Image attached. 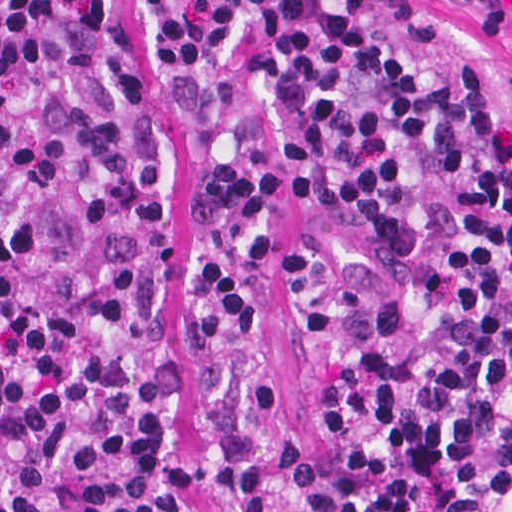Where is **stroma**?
Masks as SVG:
<instances>
[{
	"label": "stroma",
	"mask_w": 512,
	"mask_h": 512,
	"mask_svg": "<svg viewBox=\"0 0 512 512\" xmlns=\"http://www.w3.org/2000/svg\"><path fill=\"white\" fill-rule=\"evenodd\" d=\"M453 49L483 92L512 126V0H430ZM124 28L135 69L149 88L168 144L170 220L163 246L156 305L179 335L196 326V269L220 261L247 303L246 336L205 347L183 360L179 410L196 403L213 382H273L275 406L241 423L196 422L179 438L191 461L188 512H223L211 483L241 469L277 462L311 449V367L291 318L282 266L303 243L325 248L356 265L369 253L362 231L349 221L298 203L285 190L267 253H243L196 225V179L270 141L254 74V45L244 43L228 96L193 120L178 114L155 27L138 0H125Z\"/></svg>",
	"instance_id": "obj_1"
}]
</instances>
